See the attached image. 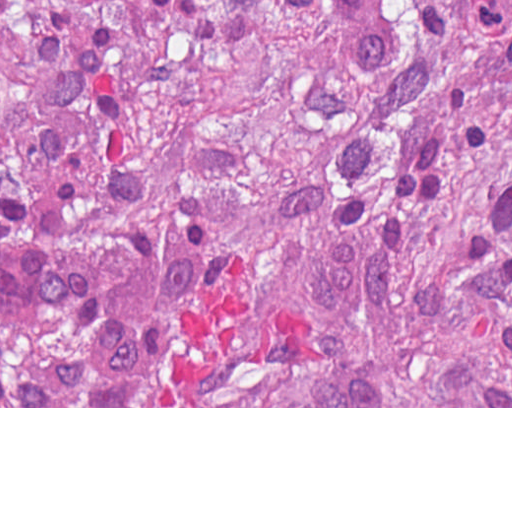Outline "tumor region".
Returning <instances> with one entry per match:
<instances>
[{
	"instance_id": "1",
	"label": "tumor region",
	"mask_w": 512,
	"mask_h": 512,
	"mask_svg": "<svg viewBox=\"0 0 512 512\" xmlns=\"http://www.w3.org/2000/svg\"><path fill=\"white\" fill-rule=\"evenodd\" d=\"M0 406H512V0H0Z\"/></svg>"
}]
</instances>
